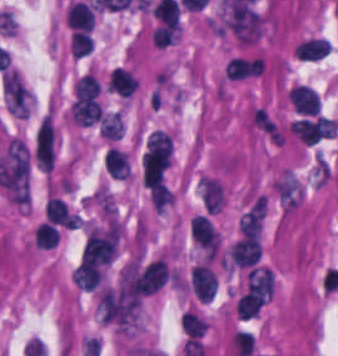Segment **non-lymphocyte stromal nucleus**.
Listing matches in <instances>:
<instances>
[{"label": "non-lymphocyte stromal nucleus", "mask_w": 338, "mask_h": 356, "mask_svg": "<svg viewBox=\"0 0 338 356\" xmlns=\"http://www.w3.org/2000/svg\"><path fill=\"white\" fill-rule=\"evenodd\" d=\"M55 134L52 122L46 113L41 117L34 132L33 157L36 168L51 170L54 160Z\"/></svg>", "instance_id": "1"}]
</instances>
